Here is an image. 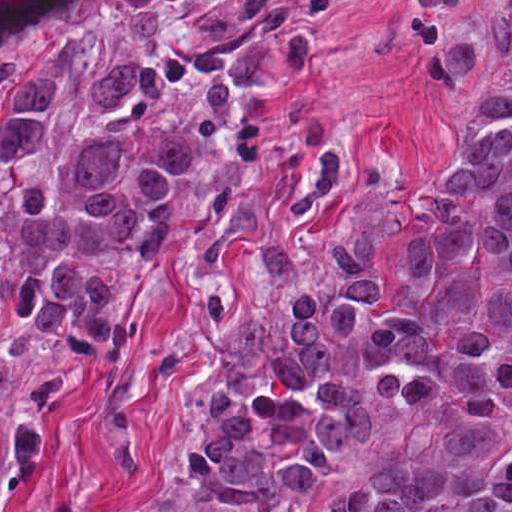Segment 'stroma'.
Here are the masks:
<instances>
[{
  "instance_id": "stroma-1",
  "label": "stroma",
  "mask_w": 512,
  "mask_h": 512,
  "mask_svg": "<svg viewBox=\"0 0 512 512\" xmlns=\"http://www.w3.org/2000/svg\"><path fill=\"white\" fill-rule=\"evenodd\" d=\"M375 414L357 443L342 451L334 466L318 481L294 492L267 512H316L327 500L359 482L374 454L394 433L400 420L392 403L378 392ZM73 512H201V496L175 479L171 468L126 487Z\"/></svg>"
}]
</instances>
